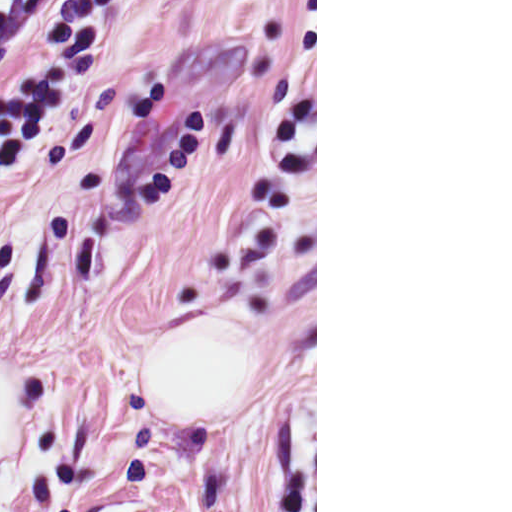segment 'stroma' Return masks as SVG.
Returning a JSON list of instances; mask_svg holds the SVG:
<instances>
[{
    "instance_id": "1",
    "label": "stroma",
    "mask_w": 512,
    "mask_h": 512,
    "mask_svg": "<svg viewBox=\"0 0 512 512\" xmlns=\"http://www.w3.org/2000/svg\"><path fill=\"white\" fill-rule=\"evenodd\" d=\"M179 0H40L0 23V80Z\"/></svg>"
}]
</instances>
